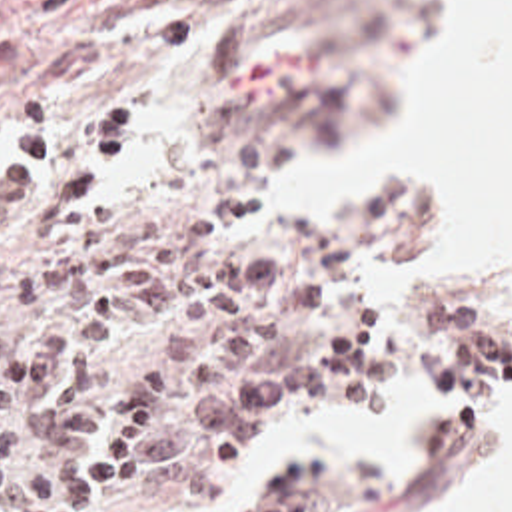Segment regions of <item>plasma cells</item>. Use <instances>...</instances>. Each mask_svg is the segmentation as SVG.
<instances>
[{"mask_svg": "<svg viewBox=\"0 0 512 512\" xmlns=\"http://www.w3.org/2000/svg\"><path fill=\"white\" fill-rule=\"evenodd\" d=\"M23 33L0 19V91ZM138 145L126 107L100 111L64 167L46 101L13 117L0 163V512H108L188 444L210 454L268 402L360 376L374 311L292 349L274 323L326 303L358 255L306 243L262 259L222 245L256 217L252 191L200 225L138 219L110 235L102 201Z\"/></svg>", "mask_w": 512, "mask_h": 512, "instance_id": "plasma-cells-1", "label": "plasma cells"}]
</instances>
